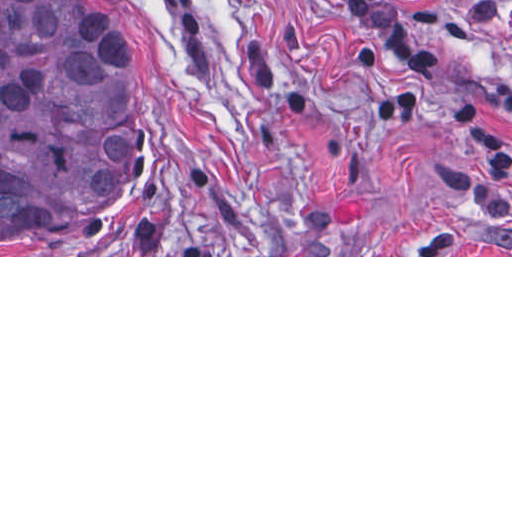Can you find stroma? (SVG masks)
Listing matches in <instances>:
<instances>
[{
    "instance_id": "stroma-1",
    "label": "stroma",
    "mask_w": 512,
    "mask_h": 512,
    "mask_svg": "<svg viewBox=\"0 0 512 512\" xmlns=\"http://www.w3.org/2000/svg\"><path fill=\"white\" fill-rule=\"evenodd\" d=\"M432 54L420 112L380 125L383 48L344 0H99L136 65L139 216L0 257H512L481 213L453 130L479 101L512 135V0H388Z\"/></svg>"
}]
</instances>
